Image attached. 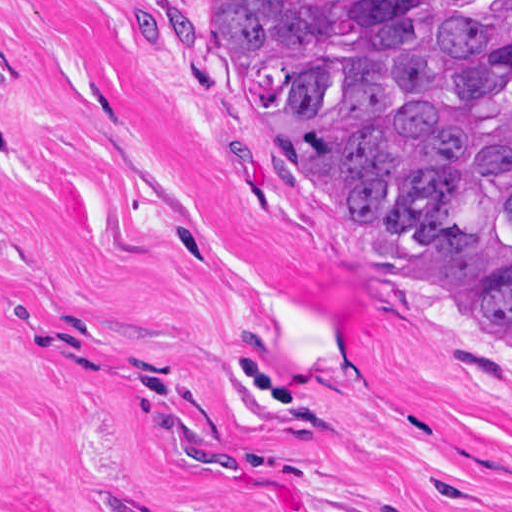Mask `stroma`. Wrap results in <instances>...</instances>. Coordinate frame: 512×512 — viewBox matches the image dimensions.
<instances>
[{
  "instance_id": "stroma-1",
  "label": "stroma",
  "mask_w": 512,
  "mask_h": 512,
  "mask_svg": "<svg viewBox=\"0 0 512 512\" xmlns=\"http://www.w3.org/2000/svg\"><path fill=\"white\" fill-rule=\"evenodd\" d=\"M424 261L160 0H0V512H512V357Z\"/></svg>"
}]
</instances>
